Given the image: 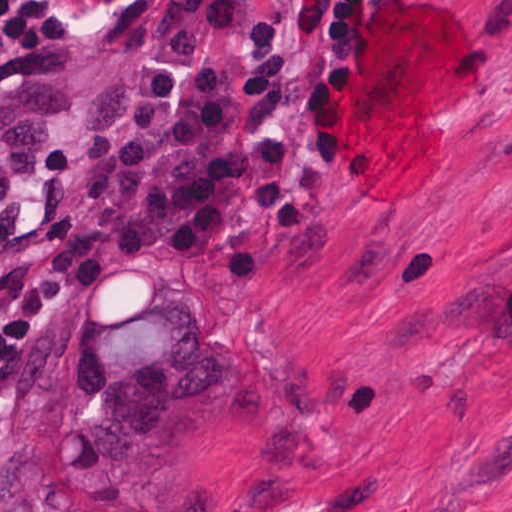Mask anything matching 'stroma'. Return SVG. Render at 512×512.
<instances>
[{"label": "stroma", "instance_id": "1", "mask_svg": "<svg viewBox=\"0 0 512 512\" xmlns=\"http://www.w3.org/2000/svg\"><path fill=\"white\" fill-rule=\"evenodd\" d=\"M0 63V272L78 229L37 129L174 0H36ZM358 144L254 297L139 255L0 385V512L512 510V0H395Z\"/></svg>", "mask_w": 512, "mask_h": 512}]
</instances>
